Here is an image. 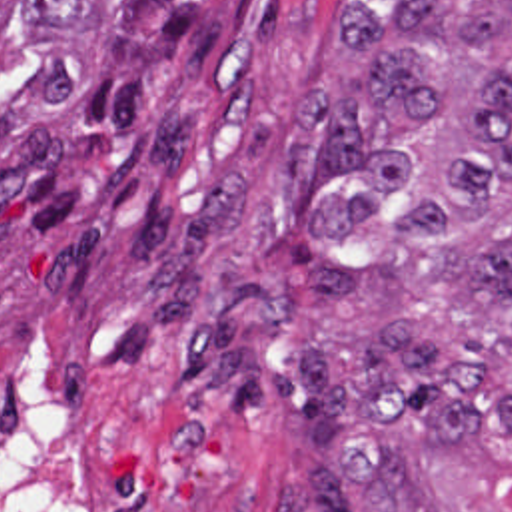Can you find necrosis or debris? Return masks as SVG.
I'll list each match as a JSON object with an SVG mask.
<instances>
[{"label":"necrosis or debris","instance_id":"necrosis-or-debris-1","mask_svg":"<svg viewBox=\"0 0 512 512\" xmlns=\"http://www.w3.org/2000/svg\"><path fill=\"white\" fill-rule=\"evenodd\" d=\"M0 512H96L66 382L10 342H0Z\"/></svg>","mask_w":512,"mask_h":512}]
</instances>
